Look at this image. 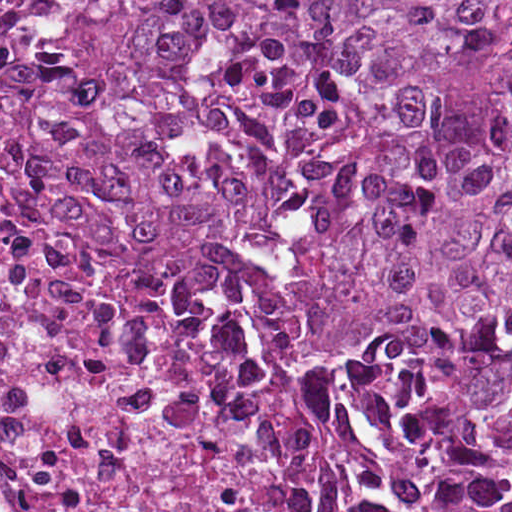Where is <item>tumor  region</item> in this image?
Here are the masks:
<instances>
[{
    "instance_id": "tumor-region-1",
    "label": "tumor region",
    "mask_w": 512,
    "mask_h": 512,
    "mask_svg": "<svg viewBox=\"0 0 512 512\" xmlns=\"http://www.w3.org/2000/svg\"><path fill=\"white\" fill-rule=\"evenodd\" d=\"M68 162L102 253L350 375L397 491L512 512L508 1H111Z\"/></svg>"
}]
</instances>
